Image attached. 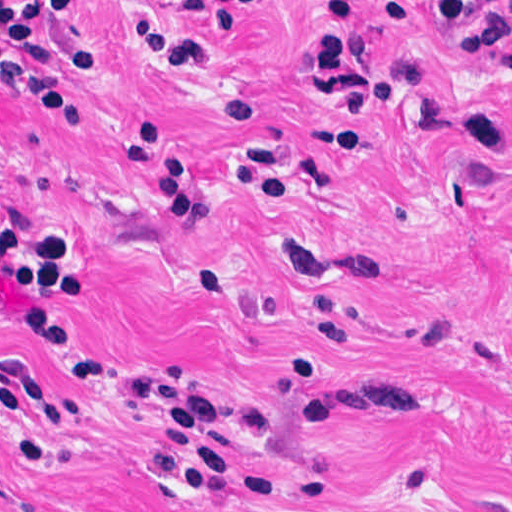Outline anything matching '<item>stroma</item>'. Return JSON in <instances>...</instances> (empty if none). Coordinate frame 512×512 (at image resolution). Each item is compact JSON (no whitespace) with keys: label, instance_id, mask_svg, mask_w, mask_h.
Wrapping results in <instances>:
<instances>
[{"label":"stroma","instance_id":"35a3bbf8","mask_svg":"<svg viewBox=\"0 0 512 512\" xmlns=\"http://www.w3.org/2000/svg\"><path fill=\"white\" fill-rule=\"evenodd\" d=\"M83 0L102 64L60 69L91 120L78 136L0 80V226L79 249L60 309L101 355L73 379L0 324V376L23 367L79 408L43 429L0 416V512H512V50L471 60L424 0L356 1L379 94L349 154L311 68L328 0H272L235 39L211 3ZM226 268L216 288L202 264ZM24 296L0 276V303ZM315 303L348 343L277 388ZM415 371L410 421H303L305 401ZM162 374L264 416L250 458L287 501L236 510L141 465L131 378Z\"/></svg>","mask_w":512,"mask_h":512}]
</instances>
